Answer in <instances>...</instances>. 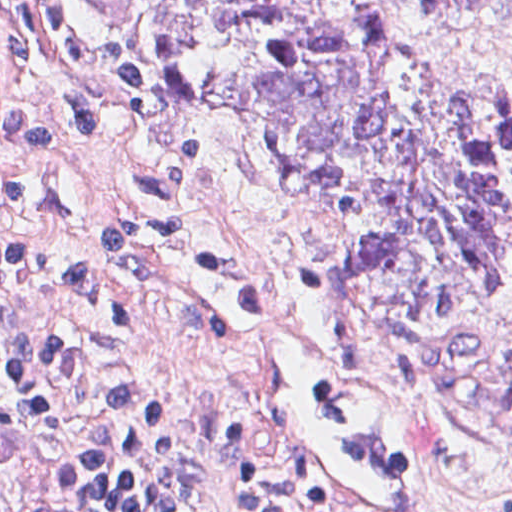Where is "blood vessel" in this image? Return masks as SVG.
Returning <instances> with one entry per match:
<instances>
[{"label":"blood vessel","instance_id":"blood-vessel-1","mask_svg":"<svg viewBox=\"0 0 512 512\" xmlns=\"http://www.w3.org/2000/svg\"><path fill=\"white\" fill-rule=\"evenodd\" d=\"M248 255L202 269V301L189 318L261 358L281 461L309 507L405 512L421 463L383 386L292 314Z\"/></svg>","mask_w":512,"mask_h":512}]
</instances>
